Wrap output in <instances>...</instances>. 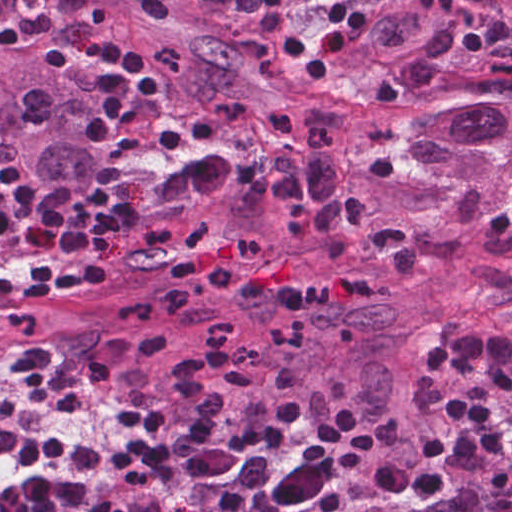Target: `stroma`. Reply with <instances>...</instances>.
I'll use <instances>...</instances> for the list:
<instances>
[{"label": "stroma", "mask_w": 512, "mask_h": 512, "mask_svg": "<svg viewBox=\"0 0 512 512\" xmlns=\"http://www.w3.org/2000/svg\"><path fill=\"white\" fill-rule=\"evenodd\" d=\"M286 41L278 35L273 54L283 62L288 73L301 71L286 55ZM328 73H333L360 96L368 109L386 108L363 85L348 82L331 70ZM49 378L51 389L18 402L4 427L15 435L103 455V462L94 466H43L62 481L91 479L153 407L125 394L109 377L88 368L67 374L49 371ZM18 384L17 371L0 369V411L6 395ZM25 467L0 458V496L11 485L18 484Z\"/></svg>", "instance_id": "1"}]
</instances>
